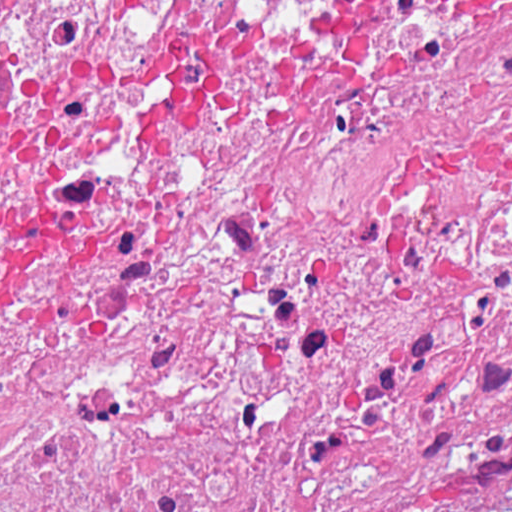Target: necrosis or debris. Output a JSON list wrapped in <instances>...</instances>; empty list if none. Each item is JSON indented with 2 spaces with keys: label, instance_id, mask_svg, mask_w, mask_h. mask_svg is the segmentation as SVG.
I'll list each match as a JSON object with an SVG mask.
<instances>
[{
  "label": "necrosis or debris",
  "instance_id": "obj_1",
  "mask_svg": "<svg viewBox=\"0 0 512 512\" xmlns=\"http://www.w3.org/2000/svg\"><path fill=\"white\" fill-rule=\"evenodd\" d=\"M0 512H512V0H0Z\"/></svg>",
  "mask_w": 512,
  "mask_h": 512
}]
</instances>
